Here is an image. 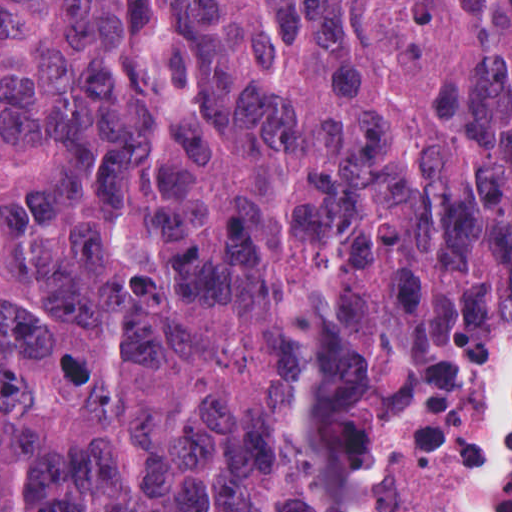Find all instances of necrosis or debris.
I'll return each mask as SVG.
<instances>
[{
    "mask_svg": "<svg viewBox=\"0 0 512 512\" xmlns=\"http://www.w3.org/2000/svg\"><path fill=\"white\" fill-rule=\"evenodd\" d=\"M481 494L482 412L459 367L424 379L354 478L314 512H479Z\"/></svg>",
    "mask_w": 512,
    "mask_h": 512,
    "instance_id": "necrosis-or-debris-1",
    "label": "necrosis or debris"
}]
</instances>
